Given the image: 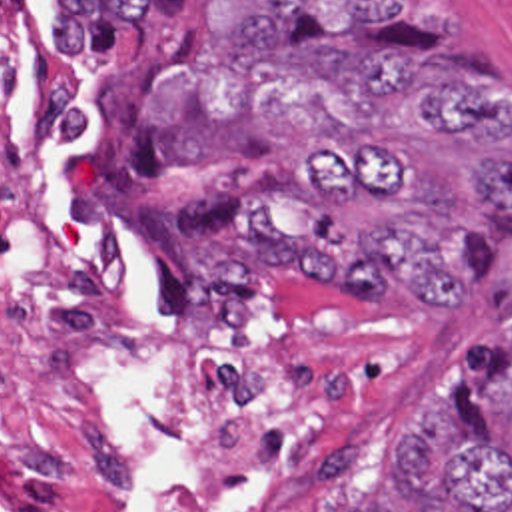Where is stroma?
I'll return each instance as SVG.
<instances>
[{
  "label": "stroma",
  "instance_id": "stroma-1",
  "mask_svg": "<svg viewBox=\"0 0 512 512\" xmlns=\"http://www.w3.org/2000/svg\"><path fill=\"white\" fill-rule=\"evenodd\" d=\"M420 49L450 53L482 67L512 89V0H444L442 29L424 23ZM60 61V59H58ZM134 49L112 45L90 63L60 61L82 211L92 255L110 259L150 313V345L164 378L198 404L226 378H208L192 360L180 303V245L198 215L212 207L218 179L184 173L164 187L138 191L108 169V117ZM466 231L494 257L498 275L462 309H404L398 301L324 303L286 291L268 301L270 360L328 358L362 374L386 422L390 512H406L394 480L392 450L426 394L442 396L462 370L474 337H504L492 295L512 279V227L490 209L466 203Z\"/></svg>",
  "mask_w": 512,
  "mask_h": 512
}]
</instances>
